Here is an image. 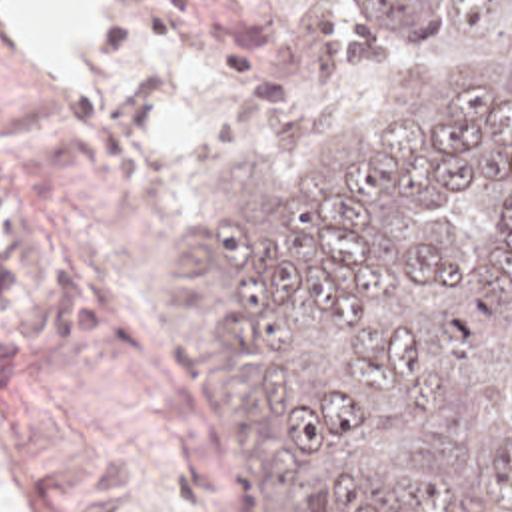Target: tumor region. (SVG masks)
<instances>
[{"label": "tumor region", "instance_id": "e687c5a6", "mask_svg": "<svg viewBox=\"0 0 512 512\" xmlns=\"http://www.w3.org/2000/svg\"><path fill=\"white\" fill-rule=\"evenodd\" d=\"M370 124L292 202L238 146L169 267L260 512H512V0H358Z\"/></svg>", "mask_w": 512, "mask_h": 512}]
</instances>
